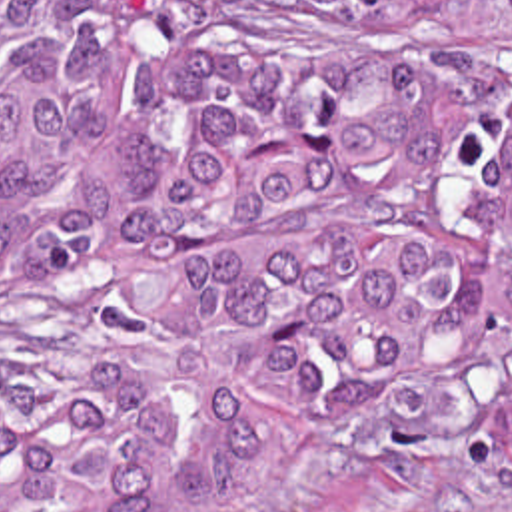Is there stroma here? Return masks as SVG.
<instances>
[{"instance_id":"35a3bbf8","label":"stroma","mask_w":512,"mask_h":512,"mask_svg":"<svg viewBox=\"0 0 512 512\" xmlns=\"http://www.w3.org/2000/svg\"><path fill=\"white\" fill-rule=\"evenodd\" d=\"M116 307L61 289H0V394L47 349H91ZM210 512H512V370L428 420H302Z\"/></svg>"}]
</instances>
